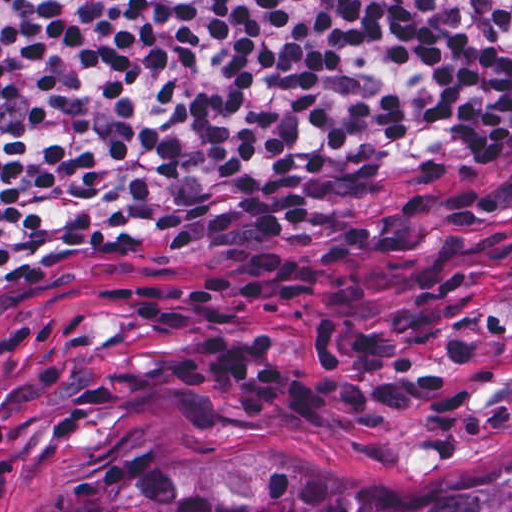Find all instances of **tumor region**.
<instances>
[{
  "label": "tumor region",
  "instance_id": "tumor-region-1",
  "mask_svg": "<svg viewBox=\"0 0 512 512\" xmlns=\"http://www.w3.org/2000/svg\"><path fill=\"white\" fill-rule=\"evenodd\" d=\"M39 512H512V461L384 476L296 450H205Z\"/></svg>",
  "mask_w": 512,
  "mask_h": 512
}]
</instances>
